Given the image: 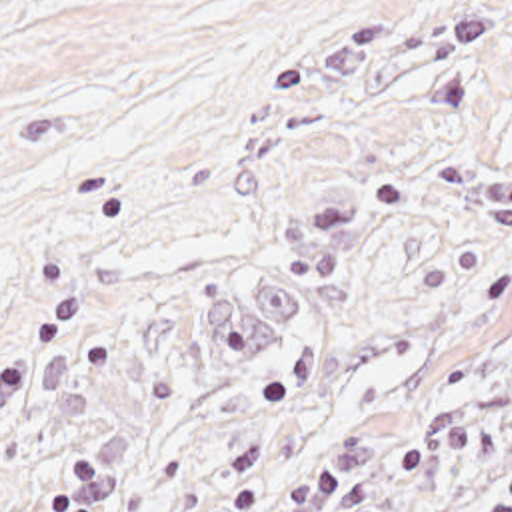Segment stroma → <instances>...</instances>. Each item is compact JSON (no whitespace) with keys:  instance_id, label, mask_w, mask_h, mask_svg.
<instances>
[{"instance_id":"35a3bbf8","label":"stroma","mask_w":512,"mask_h":512,"mask_svg":"<svg viewBox=\"0 0 512 512\" xmlns=\"http://www.w3.org/2000/svg\"><path fill=\"white\" fill-rule=\"evenodd\" d=\"M0 512H512V0H0Z\"/></svg>"}]
</instances>
